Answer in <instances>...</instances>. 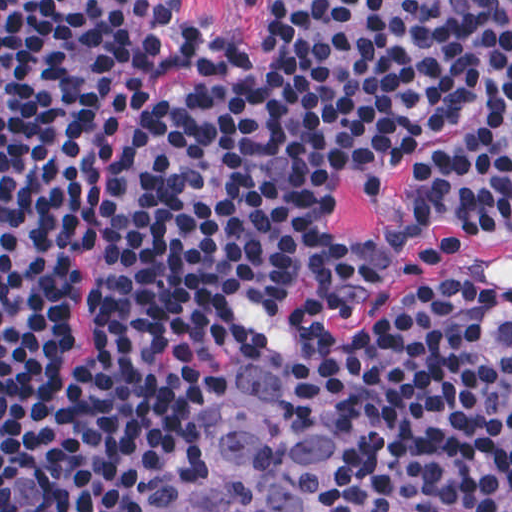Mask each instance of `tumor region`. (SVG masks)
<instances>
[{
  "label": "tumor region",
  "instance_id": "e687c5a6",
  "mask_svg": "<svg viewBox=\"0 0 512 512\" xmlns=\"http://www.w3.org/2000/svg\"><path fill=\"white\" fill-rule=\"evenodd\" d=\"M203 439L200 487L166 512H338L325 373L301 340L261 345L220 393Z\"/></svg>",
  "mask_w": 512,
  "mask_h": 512
}]
</instances>
